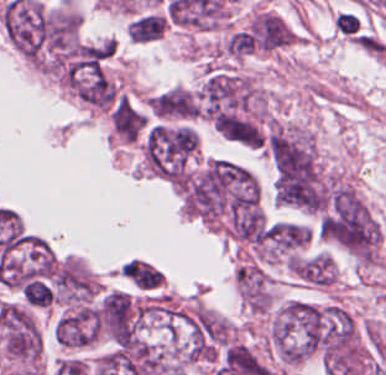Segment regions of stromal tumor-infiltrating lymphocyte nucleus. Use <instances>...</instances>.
I'll return each mask as SVG.
<instances>
[{"label": "stromal tumor-infiltrating lymphocyte nucleus", "mask_w": 386, "mask_h": 375, "mask_svg": "<svg viewBox=\"0 0 386 375\" xmlns=\"http://www.w3.org/2000/svg\"><path fill=\"white\" fill-rule=\"evenodd\" d=\"M165 180L185 175L189 165L187 122H161Z\"/></svg>", "instance_id": "obj_1"}, {"label": "stromal tumor-infiltrating lymphocyte nucleus", "mask_w": 386, "mask_h": 375, "mask_svg": "<svg viewBox=\"0 0 386 375\" xmlns=\"http://www.w3.org/2000/svg\"><path fill=\"white\" fill-rule=\"evenodd\" d=\"M334 29L341 35L358 42L362 33V23L356 15L341 12L334 19Z\"/></svg>", "instance_id": "obj_2"}]
</instances>
